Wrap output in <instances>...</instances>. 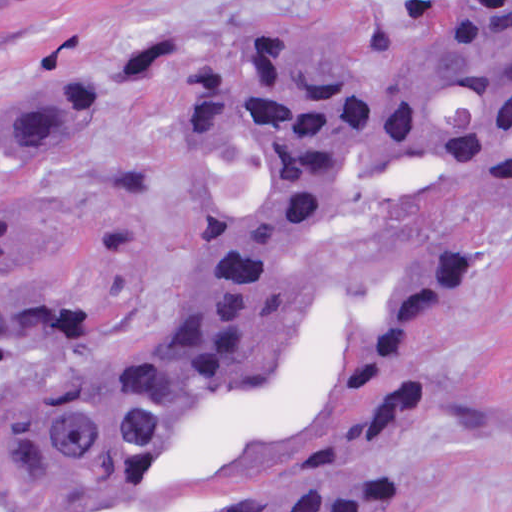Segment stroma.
Listing matches in <instances>:
<instances>
[{"instance_id":"obj_1","label":"stroma","mask_w":512,"mask_h":512,"mask_svg":"<svg viewBox=\"0 0 512 512\" xmlns=\"http://www.w3.org/2000/svg\"><path fill=\"white\" fill-rule=\"evenodd\" d=\"M446 4L14 0L0 16V104L13 89L72 74L98 101L76 153L0 162V194L32 200L75 231L21 291L82 303L106 351L155 338L187 287L182 76L255 33L317 43L376 74L427 45ZM451 233L478 250V270L428 357L460 403L402 443L388 469L409 492L402 512H512V188H443L404 212L328 215L289 255L287 272L302 282H376L416 246Z\"/></svg>"}]
</instances>
